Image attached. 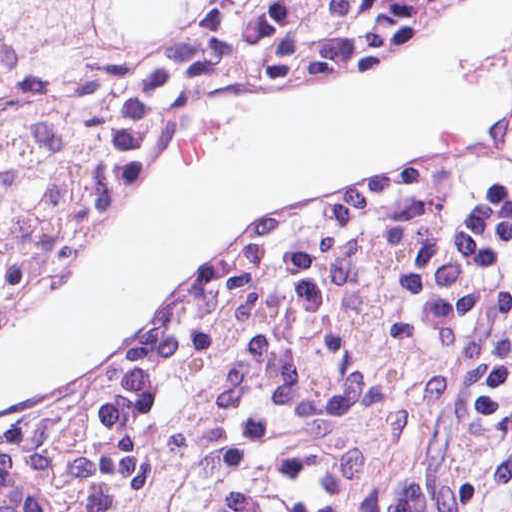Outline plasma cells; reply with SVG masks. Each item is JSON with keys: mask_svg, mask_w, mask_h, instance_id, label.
<instances>
[{"mask_svg": "<svg viewBox=\"0 0 512 512\" xmlns=\"http://www.w3.org/2000/svg\"><path fill=\"white\" fill-rule=\"evenodd\" d=\"M180 333L86 435L87 512H398L405 456L335 319Z\"/></svg>", "mask_w": 512, "mask_h": 512, "instance_id": "plasma-cells-1", "label": "plasma cells"}]
</instances>
